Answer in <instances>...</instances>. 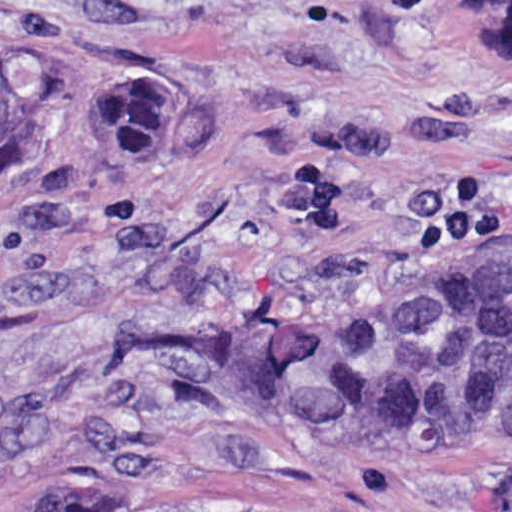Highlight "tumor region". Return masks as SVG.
<instances>
[{"label": "tumor region", "instance_id": "e687c5a6", "mask_svg": "<svg viewBox=\"0 0 512 512\" xmlns=\"http://www.w3.org/2000/svg\"><path fill=\"white\" fill-rule=\"evenodd\" d=\"M481 40L512 47V0H470ZM147 72L100 87L94 132L115 156H149L187 112ZM66 107L60 71L0 61V167L23 166ZM257 361L298 429L338 455L472 449L512 432V247L461 254L260 341ZM0 512H109L76 496Z\"/></svg>", "mask_w": 512, "mask_h": 512}]
</instances>
